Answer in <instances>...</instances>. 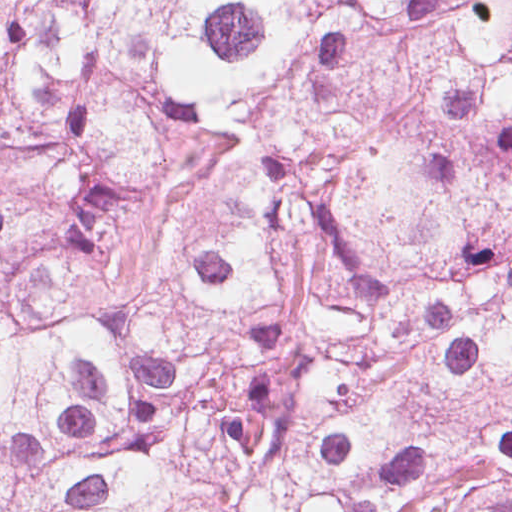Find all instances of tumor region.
<instances>
[{
  "instance_id": "tumor-region-1",
  "label": "tumor region",
  "mask_w": 512,
  "mask_h": 512,
  "mask_svg": "<svg viewBox=\"0 0 512 512\" xmlns=\"http://www.w3.org/2000/svg\"><path fill=\"white\" fill-rule=\"evenodd\" d=\"M0 512H512V0L0 28Z\"/></svg>"
}]
</instances>
